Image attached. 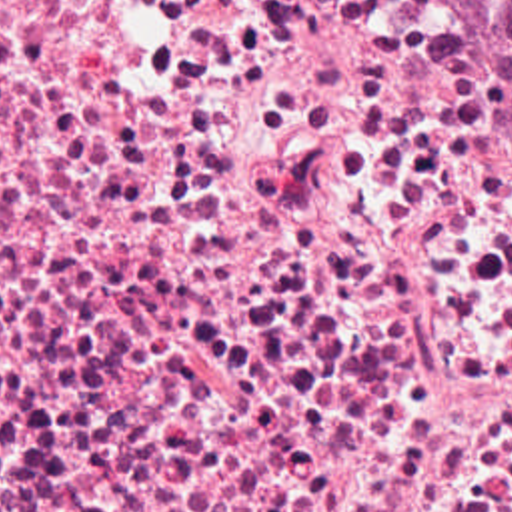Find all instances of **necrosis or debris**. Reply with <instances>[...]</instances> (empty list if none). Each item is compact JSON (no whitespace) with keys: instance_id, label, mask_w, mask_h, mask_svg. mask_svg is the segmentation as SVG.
I'll use <instances>...</instances> for the list:
<instances>
[{"instance_id":"obj_1","label":"necrosis or debris","mask_w":512,"mask_h":512,"mask_svg":"<svg viewBox=\"0 0 512 512\" xmlns=\"http://www.w3.org/2000/svg\"><path fill=\"white\" fill-rule=\"evenodd\" d=\"M0 428H512L457 4L0 0Z\"/></svg>"}]
</instances>
